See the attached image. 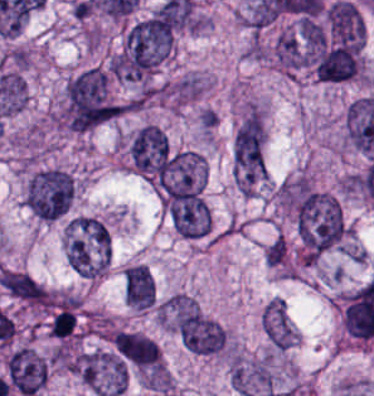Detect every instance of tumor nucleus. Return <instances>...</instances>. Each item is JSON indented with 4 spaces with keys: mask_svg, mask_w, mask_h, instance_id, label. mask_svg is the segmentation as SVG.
Wrapping results in <instances>:
<instances>
[{
    "mask_svg": "<svg viewBox=\"0 0 374 396\" xmlns=\"http://www.w3.org/2000/svg\"><path fill=\"white\" fill-rule=\"evenodd\" d=\"M296 223L303 255H318L338 243L345 232L339 202L333 194L321 190L303 193Z\"/></svg>",
    "mask_w": 374,
    "mask_h": 396,
    "instance_id": "2f306a5c",
    "label": "tumor nucleus"
},
{
    "mask_svg": "<svg viewBox=\"0 0 374 396\" xmlns=\"http://www.w3.org/2000/svg\"><path fill=\"white\" fill-rule=\"evenodd\" d=\"M116 116V106L103 69L91 67L67 88V119L71 130L86 132Z\"/></svg>",
    "mask_w": 374,
    "mask_h": 396,
    "instance_id": "8643909e",
    "label": "tumor nucleus"
},
{
    "mask_svg": "<svg viewBox=\"0 0 374 396\" xmlns=\"http://www.w3.org/2000/svg\"><path fill=\"white\" fill-rule=\"evenodd\" d=\"M172 39L170 27L150 16L126 30L120 72L123 77L143 78L165 55Z\"/></svg>",
    "mask_w": 374,
    "mask_h": 396,
    "instance_id": "5ab6c2c4",
    "label": "tumor nucleus"
},
{
    "mask_svg": "<svg viewBox=\"0 0 374 396\" xmlns=\"http://www.w3.org/2000/svg\"><path fill=\"white\" fill-rule=\"evenodd\" d=\"M73 192L68 174L56 168L41 170L27 187V207L39 218L53 221L67 212Z\"/></svg>",
    "mask_w": 374,
    "mask_h": 396,
    "instance_id": "2cbd58db",
    "label": "tumor nucleus"
},
{
    "mask_svg": "<svg viewBox=\"0 0 374 396\" xmlns=\"http://www.w3.org/2000/svg\"><path fill=\"white\" fill-rule=\"evenodd\" d=\"M234 165L244 183H254L264 173V126L254 107L234 139Z\"/></svg>",
    "mask_w": 374,
    "mask_h": 396,
    "instance_id": "3d1891a8",
    "label": "tumor nucleus"
},
{
    "mask_svg": "<svg viewBox=\"0 0 374 396\" xmlns=\"http://www.w3.org/2000/svg\"><path fill=\"white\" fill-rule=\"evenodd\" d=\"M169 152L165 132L155 125H142L129 147V158L135 169L157 179Z\"/></svg>",
    "mask_w": 374,
    "mask_h": 396,
    "instance_id": "2083b535",
    "label": "tumor nucleus"
},
{
    "mask_svg": "<svg viewBox=\"0 0 374 396\" xmlns=\"http://www.w3.org/2000/svg\"><path fill=\"white\" fill-rule=\"evenodd\" d=\"M178 330L182 342L193 352L213 353L223 344V328L197 309L178 313Z\"/></svg>",
    "mask_w": 374,
    "mask_h": 396,
    "instance_id": "8087334f",
    "label": "tumor nucleus"
},
{
    "mask_svg": "<svg viewBox=\"0 0 374 396\" xmlns=\"http://www.w3.org/2000/svg\"><path fill=\"white\" fill-rule=\"evenodd\" d=\"M313 66L317 79L326 82L350 79L359 66L357 42H335L322 48Z\"/></svg>",
    "mask_w": 374,
    "mask_h": 396,
    "instance_id": "c2bd9aea",
    "label": "tumor nucleus"
},
{
    "mask_svg": "<svg viewBox=\"0 0 374 396\" xmlns=\"http://www.w3.org/2000/svg\"><path fill=\"white\" fill-rule=\"evenodd\" d=\"M168 216L181 236L201 237L208 230V207L200 197L168 198Z\"/></svg>",
    "mask_w": 374,
    "mask_h": 396,
    "instance_id": "feef74b5",
    "label": "tumor nucleus"
},
{
    "mask_svg": "<svg viewBox=\"0 0 374 396\" xmlns=\"http://www.w3.org/2000/svg\"><path fill=\"white\" fill-rule=\"evenodd\" d=\"M113 345L124 363L158 372L159 352L151 338L140 333L120 331L114 336Z\"/></svg>",
    "mask_w": 374,
    "mask_h": 396,
    "instance_id": "3e47fb67",
    "label": "tumor nucleus"
},
{
    "mask_svg": "<svg viewBox=\"0 0 374 396\" xmlns=\"http://www.w3.org/2000/svg\"><path fill=\"white\" fill-rule=\"evenodd\" d=\"M328 28L334 40L354 47L362 46V17L355 5L335 2L327 11Z\"/></svg>",
    "mask_w": 374,
    "mask_h": 396,
    "instance_id": "f7901128",
    "label": "tumor nucleus"
},
{
    "mask_svg": "<svg viewBox=\"0 0 374 396\" xmlns=\"http://www.w3.org/2000/svg\"><path fill=\"white\" fill-rule=\"evenodd\" d=\"M0 285L28 304H42L45 298L44 289L25 272L4 269L1 271Z\"/></svg>",
    "mask_w": 374,
    "mask_h": 396,
    "instance_id": "268c6acd",
    "label": "tumor nucleus"
},
{
    "mask_svg": "<svg viewBox=\"0 0 374 396\" xmlns=\"http://www.w3.org/2000/svg\"><path fill=\"white\" fill-rule=\"evenodd\" d=\"M264 329L273 344L288 348L292 336L282 300H273L264 307Z\"/></svg>",
    "mask_w": 374,
    "mask_h": 396,
    "instance_id": "1edb0cf7",
    "label": "tumor nucleus"
},
{
    "mask_svg": "<svg viewBox=\"0 0 374 396\" xmlns=\"http://www.w3.org/2000/svg\"><path fill=\"white\" fill-rule=\"evenodd\" d=\"M275 56L286 68H299L305 64V52L294 34L281 33L275 42Z\"/></svg>",
    "mask_w": 374,
    "mask_h": 396,
    "instance_id": "962dda3e",
    "label": "tumor nucleus"
},
{
    "mask_svg": "<svg viewBox=\"0 0 374 396\" xmlns=\"http://www.w3.org/2000/svg\"><path fill=\"white\" fill-rule=\"evenodd\" d=\"M132 305L146 308L154 302V282L150 273L130 265Z\"/></svg>",
    "mask_w": 374,
    "mask_h": 396,
    "instance_id": "80c4ae96",
    "label": "tumor nucleus"
},
{
    "mask_svg": "<svg viewBox=\"0 0 374 396\" xmlns=\"http://www.w3.org/2000/svg\"><path fill=\"white\" fill-rule=\"evenodd\" d=\"M299 34L304 43L316 48L326 40V32L323 26L313 19H299Z\"/></svg>",
    "mask_w": 374,
    "mask_h": 396,
    "instance_id": "3d7bf9ca",
    "label": "tumor nucleus"
},
{
    "mask_svg": "<svg viewBox=\"0 0 374 396\" xmlns=\"http://www.w3.org/2000/svg\"><path fill=\"white\" fill-rule=\"evenodd\" d=\"M267 261L272 265H279L283 262L285 249L283 240L278 236L269 244L266 252Z\"/></svg>",
    "mask_w": 374,
    "mask_h": 396,
    "instance_id": "b15415a9",
    "label": "tumor nucleus"
}]
</instances>
